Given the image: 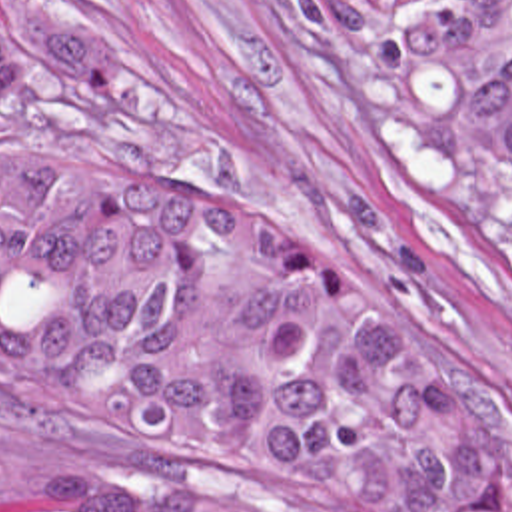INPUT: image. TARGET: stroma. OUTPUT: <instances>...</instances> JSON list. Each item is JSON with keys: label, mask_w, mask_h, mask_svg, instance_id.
I'll use <instances>...</instances> for the list:
<instances>
[{"label": "stroma", "mask_w": 512, "mask_h": 512, "mask_svg": "<svg viewBox=\"0 0 512 512\" xmlns=\"http://www.w3.org/2000/svg\"><path fill=\"white\" fill-rule=\"evenodd\" d=\"M0 40V154L295 222L480 346L512 388V272L351 154L315 0H0ZM75 473L47 428L0 422V512L45 509Z\"/></svg>", "instance_id": "obj_1"}]
</instances>
